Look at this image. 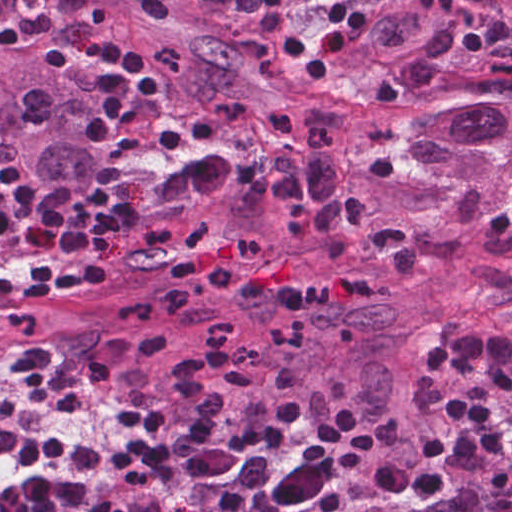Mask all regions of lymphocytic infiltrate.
Returning <instances> with one entry per match:
<instances>
[{
	"instance_id": "f902f5d3",
	"label": "lymphocytic infiltrate",
	"mask_w": 512,
	"mask_h": 512,
	"mask_svg": "<svg viewBox=\"0 0 512 512\" xmlns=\"http://www.w3.org/2000/svg\"><path fill=\"white\" fill-rule=\"evenodd\" d=\"M396 0H258L260 10L286 39L289 60L315 83L329 70L363 85L388 109H397L407 88L387 67L373 69L366 39ZM490 7L494 29L512 10V0H481ZM418 7L455 13V0H415ZM100 70L93 82L97 99L84 120V136L107 147L123 144L140 108L163 97L157 70L132 52L106 39L94 46ZM127 230V210L110 197L55 203L25 181L21 170L0 166V240L27 234L59 238L65 247L89 257L66 267L42 259L32 279L0 280V299L46 302L77 288H97L109 278L106 251ZM51 355L31 348L14 366L19 384L6 395L0 411V458L26 466L18 484L0 496V512H61L89 482L62 481L43 466H94L103 455L62 443L15 435L4 427L16 404L50 388Z\"/></svg>"
}]
</instances>
